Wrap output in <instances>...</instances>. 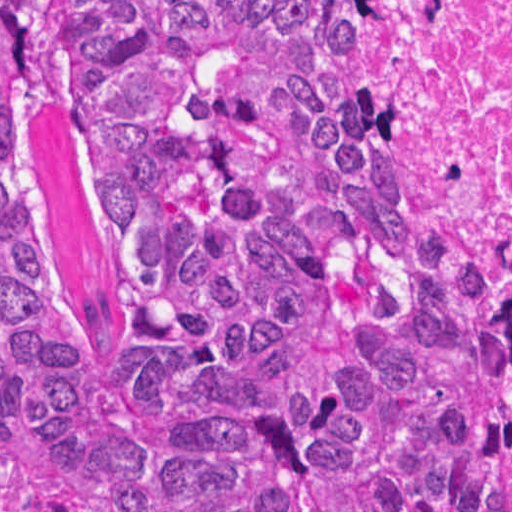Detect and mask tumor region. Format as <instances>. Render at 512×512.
Here are the masks:
<instances>
[{
  "mask_svg": "<svg viewBox=\"0 0 512 512\" xmlns=\"http://www.w3.org/2000/svg\"><path fill=\"white\" fill-rule=\"evenodd\" d=\"M0 512H512V319L322 0H0Z\"/></svg>",
  "mask_w": 512,
  "mask_h": 512,
  "instance_id": "e687c5a6",
  "label": "tumor region"
}]
</instances>
